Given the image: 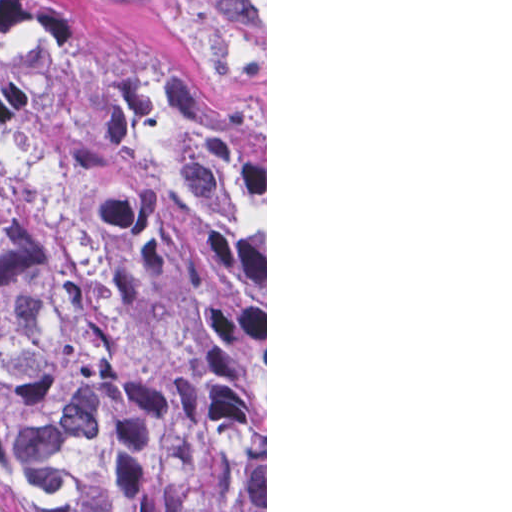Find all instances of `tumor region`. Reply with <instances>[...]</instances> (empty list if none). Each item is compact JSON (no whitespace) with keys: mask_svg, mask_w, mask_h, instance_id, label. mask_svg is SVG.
Instances as JSON below:
<instances>
[{"mask_svg":"<svg viewBox=\"0 0 512 512\" xmlns=\"http://www.w3.org/2000/svg\"><path fill=\"white\" fill-rule=\"evenodd\" d=\"M0 512H265L256 143L59 0H0Z\"/></svg>","mask_w":512,"mask_h":512,"instance_id":"1","label":"tumor region"}]
</instances>
